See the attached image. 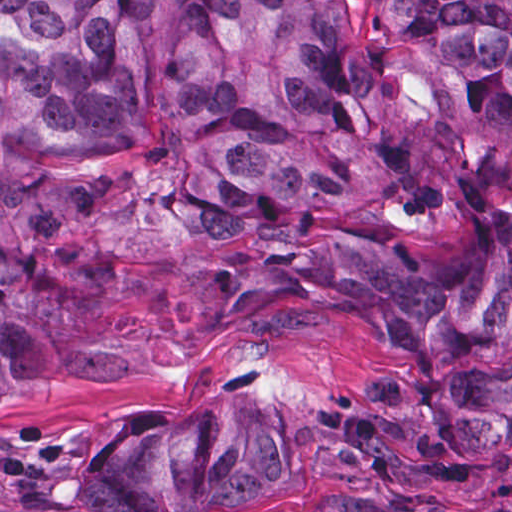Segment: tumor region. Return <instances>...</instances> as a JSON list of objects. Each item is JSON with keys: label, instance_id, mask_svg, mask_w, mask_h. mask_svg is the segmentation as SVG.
<instances>
[{"label": "tumor region", "instance_id": "tumor-region-1", "mask_svg": "<svg viewBox=\"0 0 512 512\" xmlns=\"http://www.w3.org/2000/svg\"><path fill=\"white\" fill-rule=\"evenodd\" d=\"M298 306L379 332L320 421L335 465L512 456V0H0V398ZM225 406L123 425L90 512L238 506L292 475Z\"/></svg>", "mask_w": 512, "mask_h": 512}]
</instances>
